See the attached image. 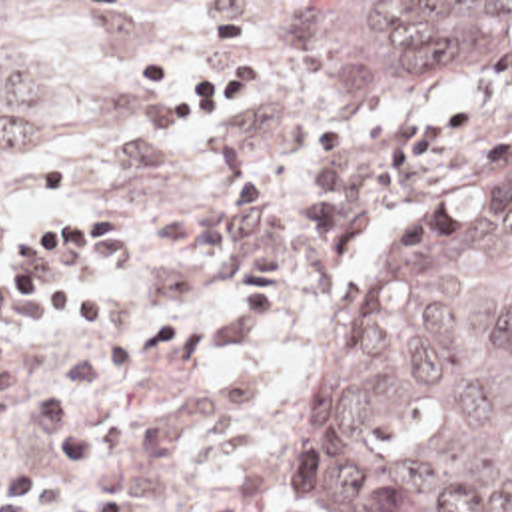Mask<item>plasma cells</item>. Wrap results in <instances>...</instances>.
<instances>
[{"mask_svg": "<svg viewBox=\"0 0 512 512\" xmlns=\"http://www.w3.org/2000/svg\"><path fill=\"white\" fill-rule=\"evenodd\" d=\"M35 319L21 312L13 284H0V427L29 423L39 431L47 451L67 463L95 465L89 429L91 405L143 369V341H125L77 361L67 375L61 357L29 343ZM205 512H253L237 499H221Z\"/></svg>", "mask_w": 512, "mask_h": 512, "instance_id": "9512152a", "label": "plasma cells"}]
</instances>
